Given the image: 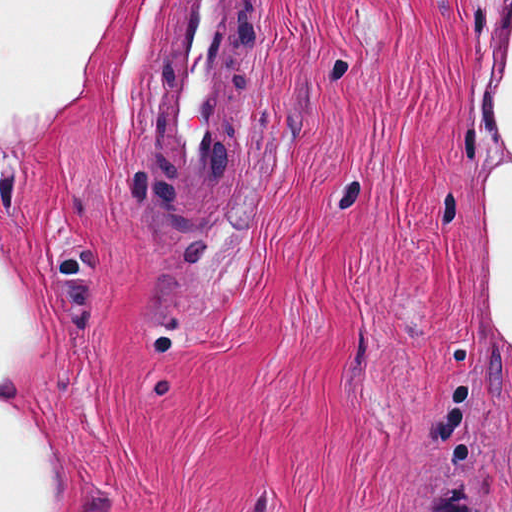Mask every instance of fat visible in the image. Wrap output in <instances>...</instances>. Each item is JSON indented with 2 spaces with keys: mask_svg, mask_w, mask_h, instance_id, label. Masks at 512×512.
I'll list each match as a JSON object with an SVG mask.
<instances>
[{
  "mask_svg": "<svg viewBox=\"0 0 512 512\" xmlns=\"http://www.w3.org/2000/svg\"><path fill=\"white\" fill-rule=\"evenodd\" d=\"M123 0H0V143L24 144L63 113ZM477 300L496 360H512V68L494 112ZM42 296L0 255V512H74L67 450L38 418Z\"/></svg>",
  "mask_w": 512,
  "mask_h": 512,
  "instance_id": "obj_1",
  "label": "fat"
}]
</instances>
